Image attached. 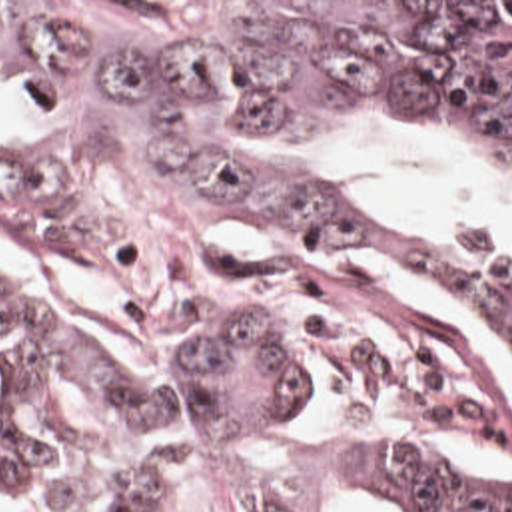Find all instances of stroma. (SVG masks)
Segmentation results:
<instances>
[{"label":"stroma","instance_id":"obj_1","mask_svg":"<svg viewBox=\"0 0 512 512\" xmlns=\"http://www.w3.org/2000/svg\"><path fill=\"white\" fill-rule=\"evenodd\" d=\"M0 2H512V0H0ZM393 134L401 138L411 140H422L432 144L436 150L462 158L474 166H478L484 156L476 150L454 146L442 138H436L428 132H422L419 128L409 126H397V124H353L345 130H341L331 146V170L339 182L341 188H345L351 196L363 202L379 204L397 212H405L411 216H417L422 220H430L440 224L442 228L450 230L452 234L480 246L496 248L502 252L512 254V244L506 242L500 234H496L490 226L464 216L460 212L430 204L419 196L385 188L369 180L365 174L359 172V152L367 144L369 138ZM508 176V174H506ZM512 180V176H508ZM0 503L7 509V512H59L27 503L19 499L15 493L0 485ZM151 512H257L245 497L207 487L195 497L187 499L175 509Z\"/></svg>","mask_w":512,"mask_h":512}]
</instances>
